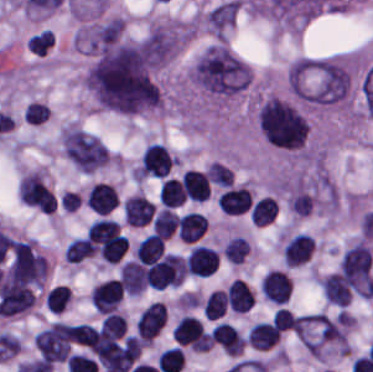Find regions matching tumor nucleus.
<instances>
[{
	"label": "tumor nucleus",
	"mask_w": 373,
	"mask_h": 372,
	"mask_svg": "<svg viewBox=\"0 0 373 372\" xmlns=\"http://www.w3.org/2000/svg\"><path fill=\"white\" fill-rule=\"evenodd\" d=\"M188 78L206 98L222 102L245 92L251 85L252 72L230 45L219 40L194 60Z\"/></svg>",
	"instance_id": "tumor-nucleus-1"
},
{
	"label": "tumor nucleus",
	"mask_w": 373,
	"mask_h": 372,
	"mask_svg": "<svg viewBox=\"0 0 373 372\" xmlns=\"http://www.w3.org/2000/svg\"><path fill=\"white\" fill-rule=\"evenodd\" d=\"M255 118L266 142L291 150L305 148L308 124L298 103L266 94L257 101Z\"/></svg>",
	"instance_id": "tumor-nucleus-2"
}]
</instances>
